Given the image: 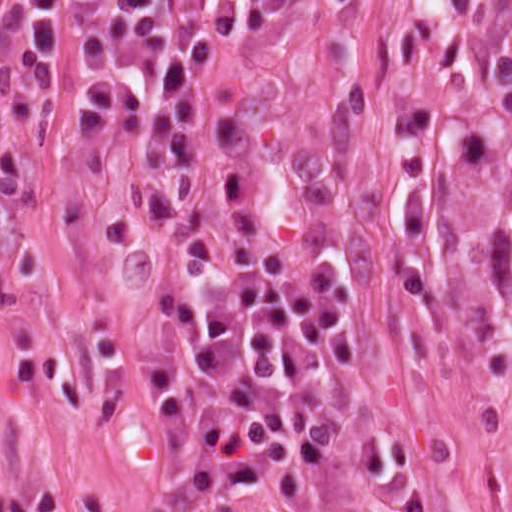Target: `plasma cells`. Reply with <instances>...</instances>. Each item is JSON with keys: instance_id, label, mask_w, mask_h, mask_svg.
<instances>
[{"instance_id": "plasma-cells-1", "label": "plasma cells", "mask_w": 512, "mask_h": 512, "mask_svg": "<svg viewBox=\"0 0 512 512\" xmlns=\"http://www.w3.org/2000/svg\"><path fill=\"white\" fill-rule=\"evenodd\" d=\"M241 0H0V202L40 206L14 157L36 107L26 86L72 91L75 41L101 103L139 134L136 289L152 340L158 264L180 272V327L145 402L164 465L198 488H238L319 427L351 369L343 302L322 278L260 247L202 151V88ZM109 426L125 349L104 317L89 329Z\"/></svg>"}]
</instances>
